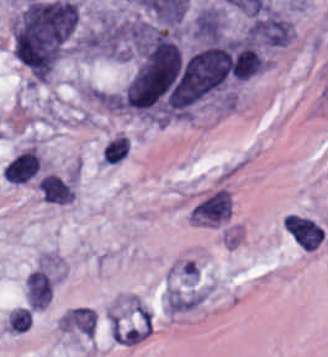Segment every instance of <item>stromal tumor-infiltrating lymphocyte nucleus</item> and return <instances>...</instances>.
<instances>
[{"instance_id":"obj_1","label":"stromal tumor-infiltrating lymphocyte nucleus","mask_w":328,"mask_h":357,"mask_svg":"<svg viewBox=\"0 0 328 357\" xmlns=\"http://www.w3.org/2000/svg\"><path fill=\"white\" fill-rule=\"evenodd\" d=\"M127 151L126 136L120 135L106 142L102 150L101 161L104 163H117L122 160Z\"/></svg>"},{"instance_id":"obj_2","label":"stromal tumor-infiltrating lymphocyte nucleus","mask_w":328,"mask_h":357,"mask_svg":"<svg viewBox=\"0 0 328 357\" xmlns=\"http://www.w3.org/2000/svg\"><path fill=\"white\" fill-rule=\"evenodd\" d=\"M31 314L27 309L16 308L9 312V331L24 332L29 329Z\"/></svg>"}]
</instances>
